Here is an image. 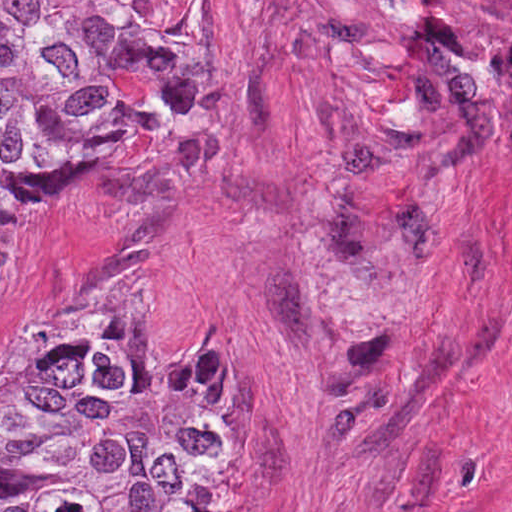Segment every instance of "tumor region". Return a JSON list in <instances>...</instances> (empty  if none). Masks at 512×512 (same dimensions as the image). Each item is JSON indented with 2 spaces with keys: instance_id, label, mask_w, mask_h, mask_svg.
Segmentation results:
<instances>
[{
  "instance_id": "obj_1",
  "label": "tumor region",
  "mask_w": 512,
  "mask_h": 512,
  "mask_svg": "<svg viewBox=\"0 0 512 512\" xmlns=\"http://www.w3.org/2000/svg\"><path fill=\"white\" fill-rule=\"evenodd\" d=\"M162 1H0V266L14 236L96 183L119 147L200 113L208 54ZM245 455L243 380L210 337L136 345L100 285L44 353L0 374V512H224Z\"/></svg>"
}]
</instances>
